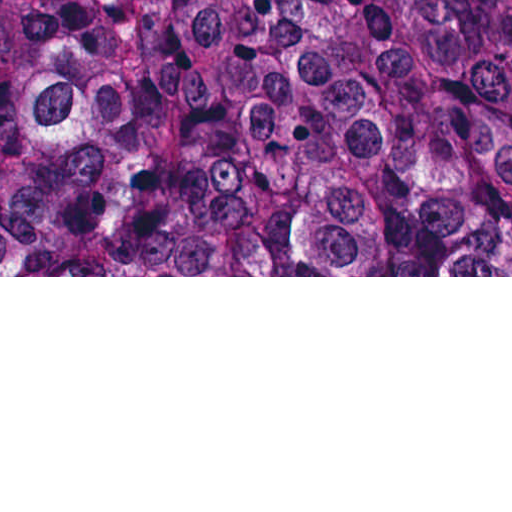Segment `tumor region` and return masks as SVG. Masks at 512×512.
<instances>
[{"label": "tumor region", "instance_id": "tumor-region-1", "mask_svg": "<svg viewBox=\"0 0 512 512\" xmlns=\"http://www.w3.org/2000/svg\"><path fill=\"white\" fill-rule=\"evenodd\" d=\"M0 268H512V0H0Z\"/></svg>", "mask_w": 512, "mask_h": 512}]
</instances>
